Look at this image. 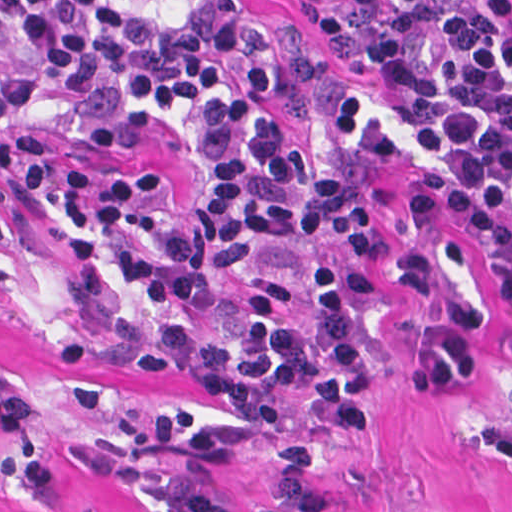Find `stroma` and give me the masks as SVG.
Instances as JSON below:
<instances>
[{
  "mask_svg": "<svg viewBox=\"0 0 512 512\" xmlns=\"http://www.w3.org/2000/svg\"><path fill=\"white\" fill-rule=\"evenodd\" d=\"M277 32L278 86L269 113L292 141L313 135L321 78L359 81L320 24L291 0H245ZM50 141L110 169L140 172L167 184L180 202H194V170L151 132L103 149L65 132ZM415 163L399 154L371 169L361 194L374 211L383 244L420 237L457 252L484 292L478 296L473 373L460 388L432 389L415 380L430 321L411 292L374 294L367 319L371 369L369 420L349 440L334 434L315 405L280 388L267 394V418L314 447L310 490L328 512H512V292L499 279L473 228L417 214ZM6 227L0 239V368L24 409L20 427H0V512H149L139 491L101 475L84 454L92 436H106L116 400L173 405L215 418L230 415L193 380L146 378L102 363L93 368L104 402L94 413L68 403L57 369L64 338L76 330L112 331L125 311H105L50 263L33 224L0 184ZM199 321H239L241 305L166 309ZM232 512H259L274 491L275 464L263 452H238L215 469Z\"/></svg>",
  "mask_w": 512,
  "mask_h": 512,
  "instance_id": "stroma-1",
  "label": "stroma"
}]
</instances>
